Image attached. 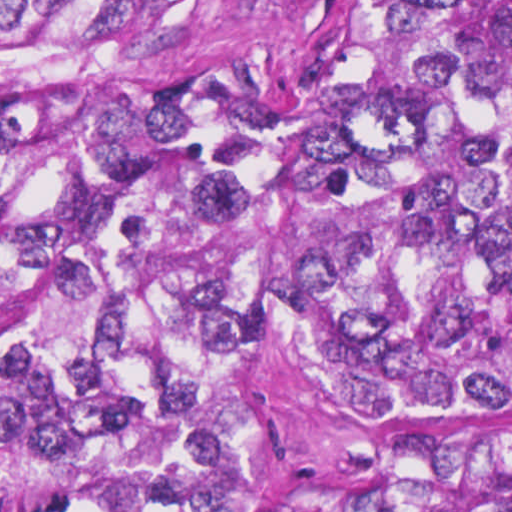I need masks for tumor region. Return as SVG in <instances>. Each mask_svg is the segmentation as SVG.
Returning <instances> with one entry per match:
<instances>
[{"label":"tumor region","instance_id":"obj_1","mask_svg":"<svg viewBox=\"0 0 512 512\" xmlns=\"http://www.w3.org/2000/svg\"><path fill=\"white\" fill-rule=\"evenodd\" d=\"M0 512H512V0H0Z\"/></svg>","mask_w":512,"mask_h":512}]
</instances>
